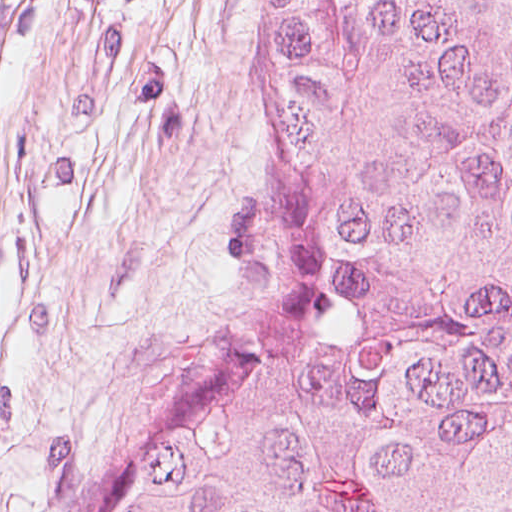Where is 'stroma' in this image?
<instances>
[{
	"label": "stroma",
	"instance_id": "35a3bbf8",
	"mask_svg": "<svg viewBox=\"0 0 512 512\" xmlns=\"http://www.w3.org/2000/svg\"><path fill=\"white\" fill-rule=\"evenodd\" d=\"M271 0H0V512L257 333L245 173Z\"/></svg>",
	"mask_w": 512,
	"mask_h": 512
}]
</instances>
